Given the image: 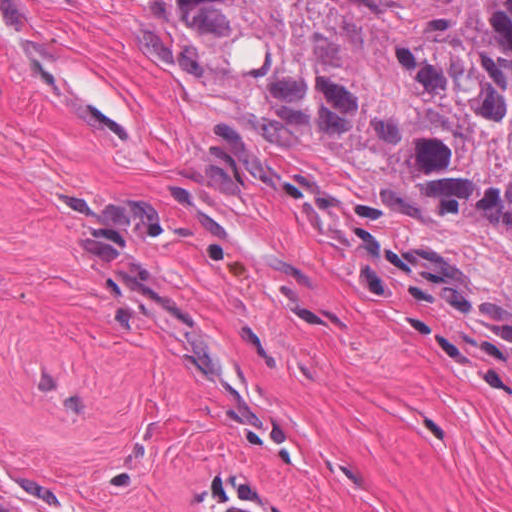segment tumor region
Segmentation results:
<instances>
[{
	"label": "tumor region",
	"instance_id": "obj_1",
	"mask_svg": "<svg viewBox=\"0 0 512 512\" xmlns=\"http://www.w3.org/2000/svg\"><path fill=\"white\" fill-rule=\"evenodd\" d=\"M206 59L253 30L294 133L409 204L512 231V0H175ZM0 512H14L0 507Z\"/></svg>",
	"mask_w": 512,
	"mask_h": 512
}]
</instances>
